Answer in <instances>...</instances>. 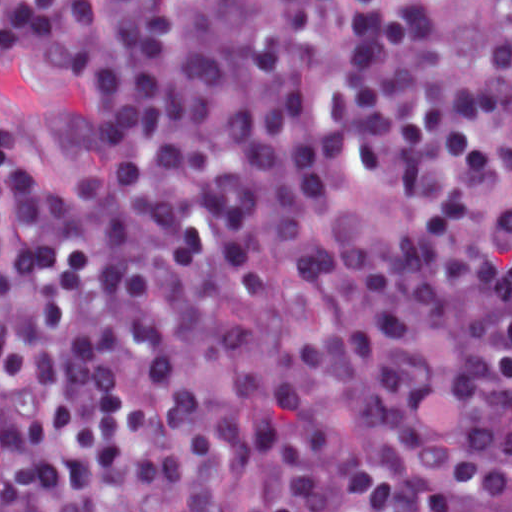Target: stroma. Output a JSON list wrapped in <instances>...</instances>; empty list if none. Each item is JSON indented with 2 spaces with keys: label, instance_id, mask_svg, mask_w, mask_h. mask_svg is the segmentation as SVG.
<instances>
[{
  "label": "stroma",
  "instance_id": "35a3bbf8",
  "mask_svg": "<svg viewBox=\"0 0 512 512\" xmlns=\"http://www.w3.org/2000/svg\"><path fill=\"white\" fill-rule=\"evenodd\" d=\"M18 1V0H4ZM472 48L512 95V61L471 25L462 0H449ZM1 110L30 167L42 177H80L91 168L86 126L72 98L58 51L37 42L14 48L1 62L0 0V512H1Z\"/></svg>",
  "mask_w": 512,
  "mask_h": 512
}]
</instances>
